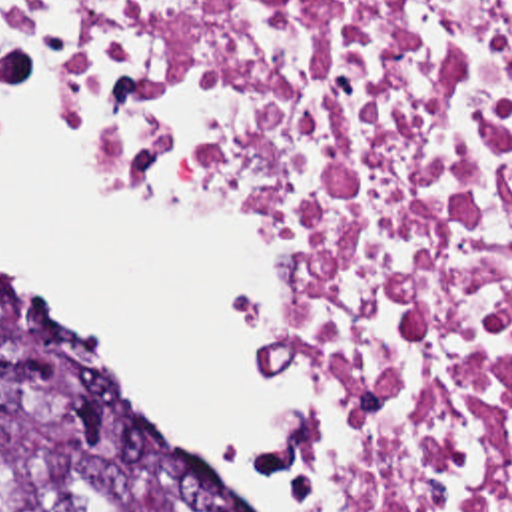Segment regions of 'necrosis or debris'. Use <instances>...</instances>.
I'll list each match as a JSON object with an SVG mask.
<instances>
[{"label":"necrosis or debris","mask_w":512,"mask_h":512,"mask_svg":"<svg viewBox=\"0 0 512 512\" xmlns=\"http://www.w3.org/2000/svg\"><path fill=\"white\" fill-rule=\"evenodd\" d=\"M107 144L293 262L331 512H512V0H3Z\"/></svg>","instance_id":"necrosis-or-debris-1"}]
</instances>
